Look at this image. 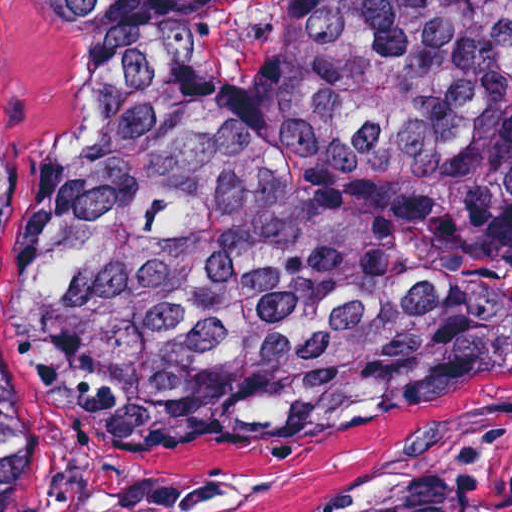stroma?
<instances>
[{
  "mask_svg": "<svg viewBox=\"0 0 512 512\" xmlns=\"http://www.w3.org/2000/svg\"><path fill=\"white\" fill-rule=\"evenodd\" d=\"M71 59L43 0H0V108L26 230L57 140ZM32 477L11 512H438L462 487L475 437L512 408V349L480 353L401 407L195 459L125 438L69 362L19 331Z\"/></svg>",
  "mask_w": 512,
  "mask_h": 512,
  "instance_id": "1",
  "label": "stroma"
}]
</instances>
